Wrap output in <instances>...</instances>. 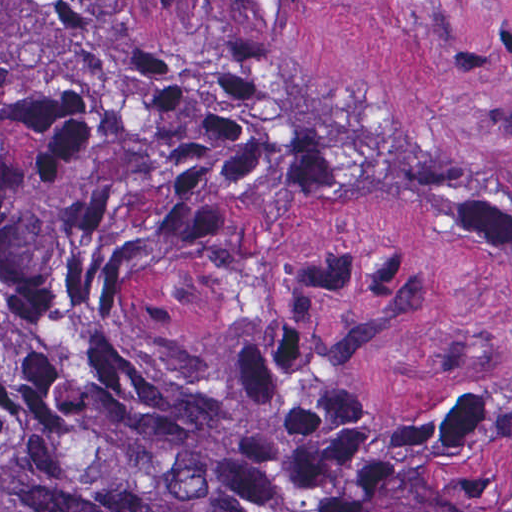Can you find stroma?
Here are the masks:
<instances>
[{"label":"stroma","instance_id":"obj_1","mask_svg":"<svg viewBox=\"0 0 512 512\" xmlns=\"http://www.w3.org/2000/svg\"><path fill=\"white\" fill-rule=\"evenodd\" d=\"M153 52L512 190V0H127ZM155 328L217 356L292 351L381 411L448 418L512 366V292L475 220L338 195L319 168L194 237L112 256Z\"/></svg>","mask_w":512,"mask_h":512}]
</instances>
